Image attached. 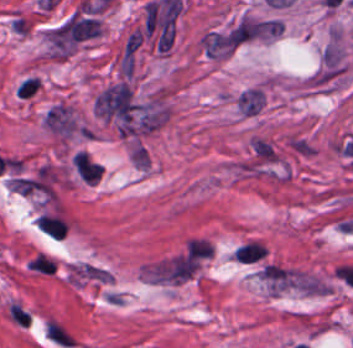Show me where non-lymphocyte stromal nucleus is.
Instances as JSON below:
<instances>
[{
    "label": "non-lymphocyte stromal nucleus",
    "instance_id": "obj_1",
    "mask_svg": "<svg viewBox=\"0 0 353 348\" xmlns=\"http://www.w3.org/2000/svg\"><path fill=\"white\" fill-rule=\"evenodd\" d=\"M42 331L70 348L65 326L54 317H47L44 320Z\"/></svg>",
    "mask_w": 353,
    "mask_h": 348
},
{
    "label": "non-lymphocyte stromal nucleus",
    "instance_id": "obj_2",
    "mask_svg": "<svg viewBox=\"0 0 353 348\" xmlns=\"http://www.w3.org/2000/svg\"><path fill=\"white\" fill-rule=\"evenodd\" d=\"M290 149L300 156H311L313 149L305 137L294 136L289 139Z\"/></svg>",
    "mask_w": 353,
    "mask_h": 348
}]
</instances>
